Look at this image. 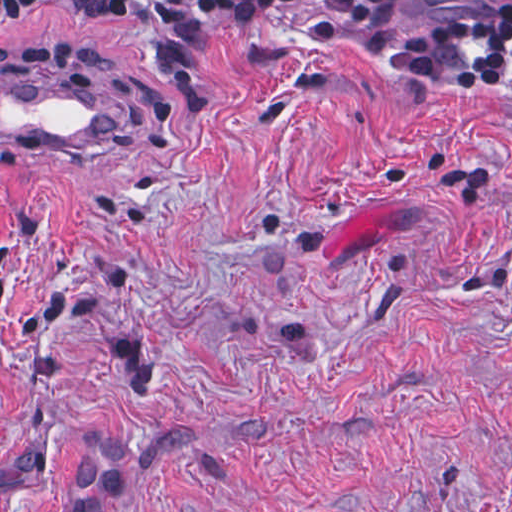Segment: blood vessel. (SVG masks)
<instances>
[{
  "mask_svg": "<svg viewBox=\"0 0 512 512\" xmlns=\"http://www.w3.org/2000/svg\"><path fill=\"white\" fill-rule=\"evenodd\" d=\"M116 145L111 75L0 69V153L98 158L110 154Z\"/></svg>",
  "mask_w": 512,
  "mask_h": 512,
  "instance_id": "1",
  "label": "blood vessel"
}]
</instances>
